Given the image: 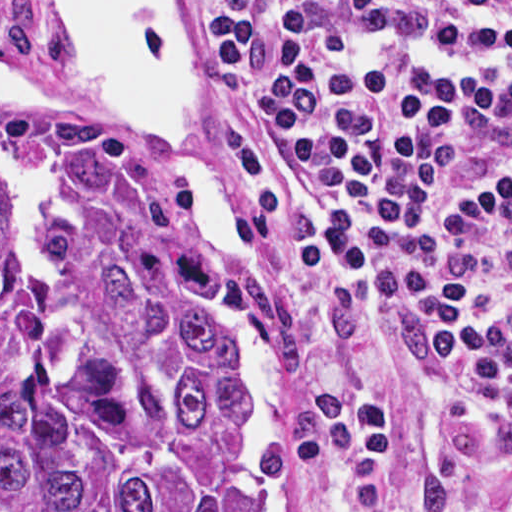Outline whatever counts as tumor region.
<instances>
[{"label":"tumor region","mask_w":512,"mask_h":512,"mask_svg":"<svg viewBox=\"0 0 512 512\" xmlns=\"http://www.w3.org/2000/svg\"><path fill=\"white\" fill-rule=\"evenodd\" d=\"M201 238L1 98V512H244Z\"/></svg>","instance_id":"obj_1"}]
</instances>
